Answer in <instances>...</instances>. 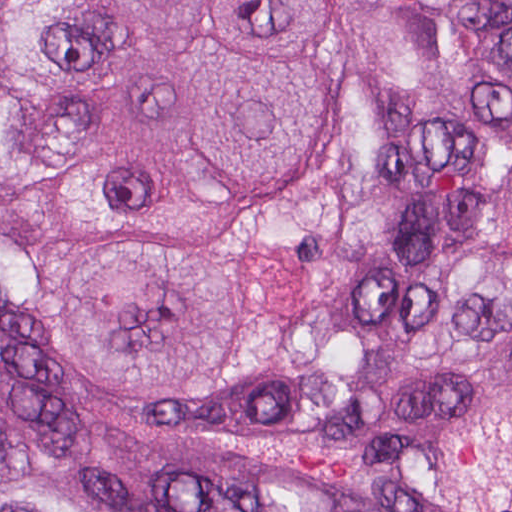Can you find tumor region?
Here are the masks:
<instances>
[{
  "label": "tumor region",
  "mask_w": 512,
  "mask_h": 512,
  "mask_svg": "<svg viewBox=\"0 0 512 512\" xmlns=\"http://www.w3.org/2000/svg\"><path fill=\"white\" fill-rule=\"evenodd\" d=\"M362 152L296 243L263 401L179 437L352 461L445 512H512V0H343ZM334 0H0V195L94 255L53 290L66 368L217 401L260 357L238 244L348 126ZM61 260L0 214V512H92L89 455L21 351ZM106 512H358L277 484H112Z\"/></svg>",
  "instance_id": "tumor-region-1"
}]
</instances>
